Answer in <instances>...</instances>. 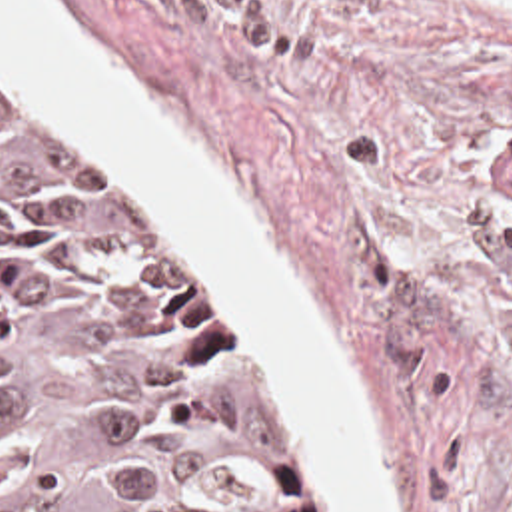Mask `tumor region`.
I'll use <instances>...</instances> for the list:
<instances>
[{"mask_svg": "<svg viewBox=\"0 0 512 512\" xmlns=\"http://www.w3.org/2000/svg\"><path fill=\"white\" fill-rule=\"evenodd\" d=\"M0 512H343L241 298L1 62Z\"/></svg>", "mask_w": 512, "mask_h": 512, "instance_id": "obj_1", "label": "tumor region"}]
</instances>
